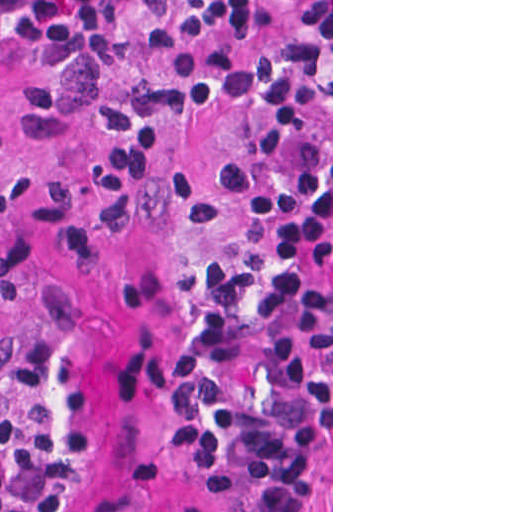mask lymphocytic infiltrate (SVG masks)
Returning <instances> with one entry per match:
<instances>
[{
	"label": "lymphocytic infiltrate",
	"mask_w": 512,
	"mask_h": 512,
	"mask_svg": "<svg viewBox=\"0 0 512 512\" xmlns=\"http://www.w3.org/2000/svg\"><path fill=\"white\" fill-rule=\"evenodd\" d=\"M291 0H18L0 11V89L37 70L98 76L101 127L76 170L0 157V260L114 236L168 156L177 82L198 57L253 46ZM235 105L254 141L240 254L211 265L170 336L165 445L219 512H302L331 438V113L321 51L283 33L245 52ZM103 407L53 331L0 360V512H57Z\"/></svg>",
	"instance_id": "f902f5d3"
}]
</instances>
